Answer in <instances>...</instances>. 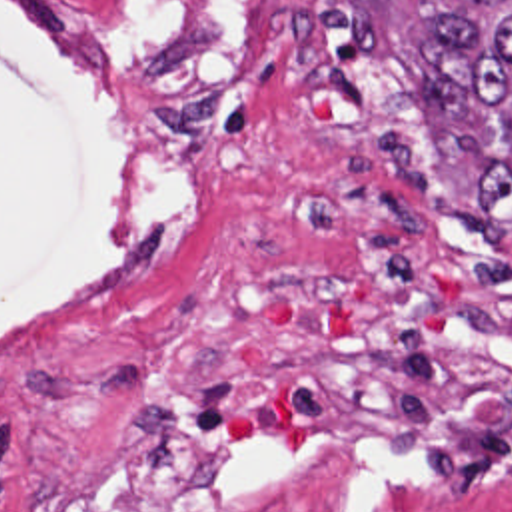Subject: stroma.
I'll list each match as a JSON object with an SVG mask.
<instances>
[{"instance_id": "35a3bbf8", "label": "stroma", "mask_w": 512, "mask_h": 512, "mask_svg": "<svg viewBox=\"0 0 512 512\" xmlns=\"http://www.w3.org/2000/svg\"><path fill=\"white\" fill-rule=\"evenodd\" d=\"M390 22L424 96L410 52L430 20L412 2L390 0ZM434 120L448 188L466 210L478 168ZM284 156L286 130L236 56L222 138L210 152H182L108 126L0 4L1 427L46 449H86L128 403L134 352L170 298L296 264L280 210ZM466 234L512 266V234L494 248ZM276 512L512 507L368 459Z\"/></svg>"}]
</instances>
